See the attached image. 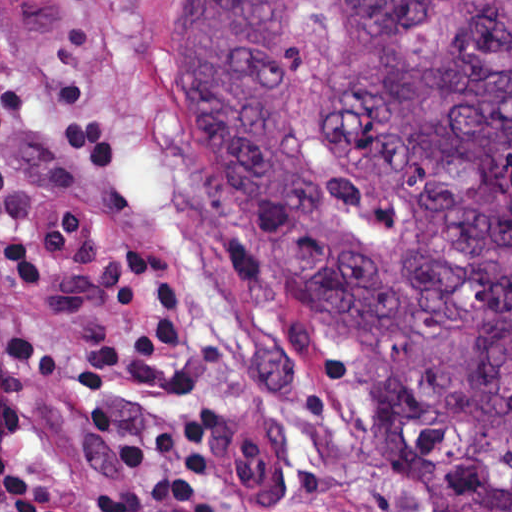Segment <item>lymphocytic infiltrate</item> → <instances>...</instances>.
Here are the masks:
<instances>
[{"label":"lymphocytic infiltrate","instance_id":"lymphocytic-infiltrate-1","mask_svg":"<svg viewBox=\"0 0 512 512\" xmlns=\"http://www.w3.org/2000/svg\"><path fill=\"white\" fill-rule=\"evenodd\" d=\"M82 412L117 489L105 501H73L26 457L1 450V512H198L205 422L157 364L85 354Z\"/></svg>","mask_w":512,"mask_h":512}]
</instances>
